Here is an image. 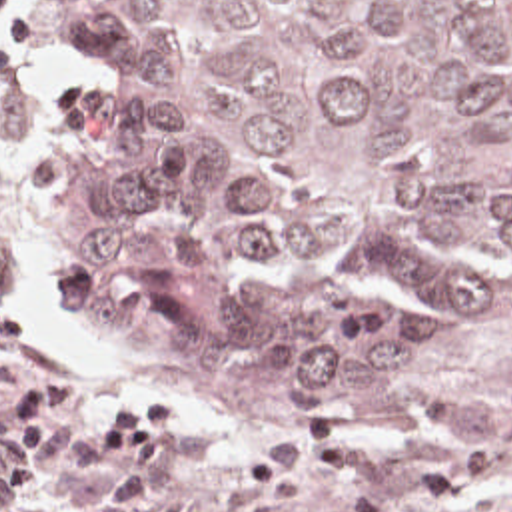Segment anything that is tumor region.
Returning <instances> with one entry per match:
<instances>
[{
  "mask_svg": "<svg viewBox=\"0 0 512 512\" xmlns=\"http://www.w3.org/2000/svg\"><path fill=\"white\" fill-rule=\"evenodd\" d=\"M68 322L240 426L427 410L512 294V0H40Z\"/></svg>",
  "mask_w": 512,
  "mask_h": 512,
  "instance_id": "obj_1",
  "label": "tumor region"
}]
</instances>
